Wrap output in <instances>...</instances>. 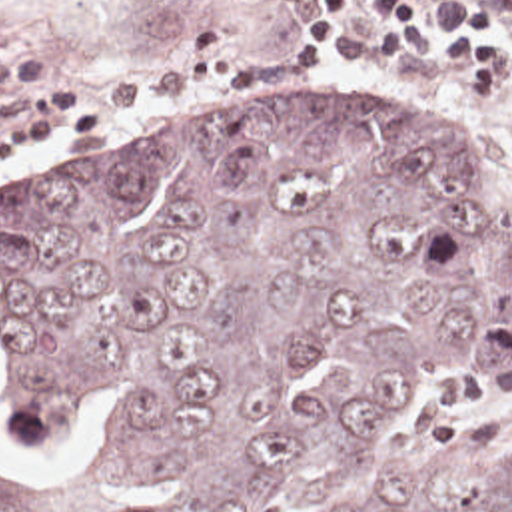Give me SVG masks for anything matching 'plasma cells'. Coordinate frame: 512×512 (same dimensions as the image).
Segmentation results:
<instances>
[{"mask_svg":"<svg viewBox=\"0 0 512 512\" xmlns=\"http://www.w3.org/2000/svg\"><path fill=\"white\" fill-rule=\"evenodd\" d=\"M492 15H512V0H480ZM37 75L29 47H0V83H27ZM301 81V61L289 55H247L239 51L237 29L201 25L183 43L173 63L157 75L109 83L97 95L101 107L161 103L197 91L281 89Z\"/></svg>","mask_w":512,"mask_h":512,"instance_id":"obj_1","label":"plasma cells"}]
</instances>
